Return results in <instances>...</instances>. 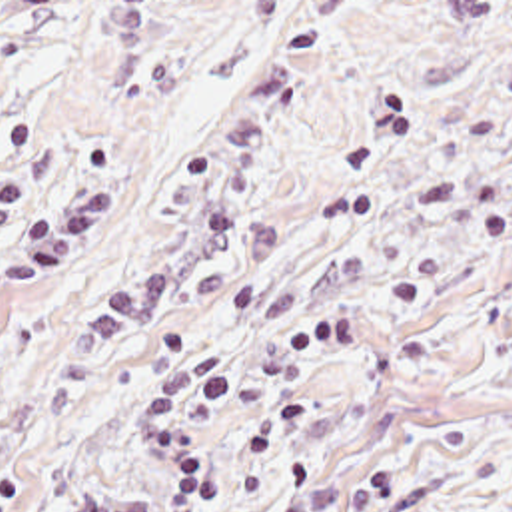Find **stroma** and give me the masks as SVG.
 Instances as JSON below:
<instances>
[{
  "instance_id": "35a3bbf8",
  "label": "stroma",
  "mask_w": 512,
  "mask_h": 512,
  "mask_svg": "<svg viewBox=\"0 0 512 512\" xmlns=\"http://www.w3.org/2000/svg\"><path fill=\"white\" fill-rule=\"evenodd\" d=\"M0 512H512V0H0Z\"/></svg>"
}]
</instances>
